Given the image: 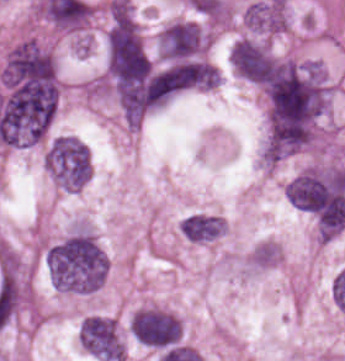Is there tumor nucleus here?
I'll return each instance as SVG.
<instances>
[{"label": "tumor nucleus", "instance_id": "8643909e", "mask_svg": "<svg viewBox=\"0 0 345 361\" xmlns=\"http://www.w3.org/2000/svg\"><path fill=\"white\" fill-rule=\"evenodd\" d=\"M129 330L148 347L163 349L178 344L181 340L179 320L173 314L155 308L135 311Z\"/></svg>", "mask_w": 345, "mask_h": 361}, {"label": "tumor nucleus", "instance_id": "5ab6c2c4", "mask_svg": "<svg viewBox=\"0 0 345 361\" xmlns=\"http://www.w3.org/2000/svg\"><path fill=\"white\" fill-rule=\"evenodd\" d=\"M79 339L87 353L104 361H122V340L114 320L110 317H84Z\"/></svg>", "mask_w": 345, "mask_h": 361}, {"label": "tumor nucleus", "instance_id": "2f306a5c", "mask_svg": "<svg viewBox=\"0 0 345 361\" xmlns=\"http://www.w3.org/2000/svg\"><path fill=\"white\" fill-rule=\"evenodd\" d=\"M46 166L63 186L78 189L90 177V150L78 137L69 134L56 136L46 150Z\"/></svg>", "mask_w": 345, "mask_h": 361}, {"label": "tumor nucleus", "instance_id": "3d1891a8", "mask_svg": "<svg viewBox=\"0 0 345 361\" xmlns=\"http://www.w3.org/2000/svg\"><path fill=\"white\" fill-rule=\"evenodd\" d=\"M206 35L194 23L175 21L158 36V46L163 57L188 59L195 57L205 47Z\"/></svg>", "mask_w": 345, "mask_h": 361}, {"label": "tumor nucleus", "instance_id": "8087334f", "mask_svg": "<svg viewBox=\"0 0 345 361\" xmlns=\"http://www.w3.org/2000/svg\"><path fill=\"white\" fill-rule=\"evenodd\" d=\"M245 22L254 31H274V10L269 2L258 1L247 7Z\"/></svg>", "mask_w": 345, "mask_h": 361}, {"label": "tumor nucleus", "instance_id": "2083b535", "mask_svg": "<svg viewBox=\"0 0 345 361\" xmlns=\"http://www.w3.org/2000/svg\"><path fill=\"white\" fill-rule=\"evenodd\" d=\"M179 228L187 240L206 242L221 233V219L216 215L193 213L182 220Z\"/></svg>", "mask_w": 345, "mask_h": 361}, {"label": "tumor nucleus", "instance_id": "2cbd58db", "mask_svg": "<svg viewBox=\"0 0 345 361\" xmlns=\"http://www.w3.org/2000/svg\"><path fill=\"white\" fill-rule=\"evenodd\" d=\"M230 59L234 71L239 76L263 85L276 67L275 58L269 49L252 39H238L233 46Z\"/></svg>", "mask_w": 345, "mask_h": 361}]
</instances>
